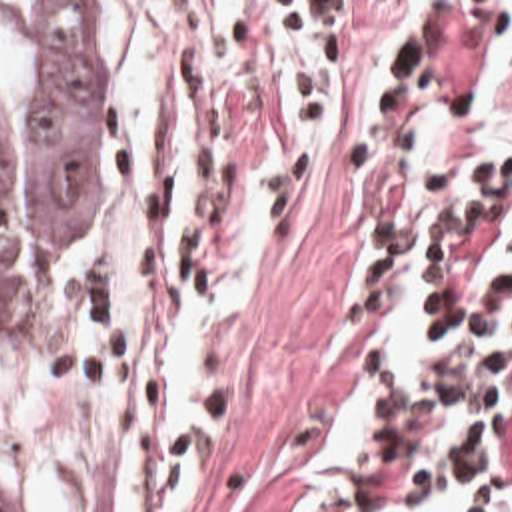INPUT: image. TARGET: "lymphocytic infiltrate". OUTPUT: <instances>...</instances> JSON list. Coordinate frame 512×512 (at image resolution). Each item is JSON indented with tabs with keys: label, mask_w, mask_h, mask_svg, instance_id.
Wrapping results in <instances>:
<instances>
[{
	"label": "lymphocytic infiltrate",
	"mask_w": 512,
	"mask_h": 512,
	"mask_svg": "<svg viewBox=\"0 0 512 512\" xmlns=\"http://www.w3.org/2000/svg\"><path fill=\"white\" fill-rule=\"evenodd\" d=\"M378 423L330 512H512V76L442 142L418 204L372 242Z\"/></svg>",
	"instance_id": "lymphocytic-infiltrate-1"
}]
</instances>
